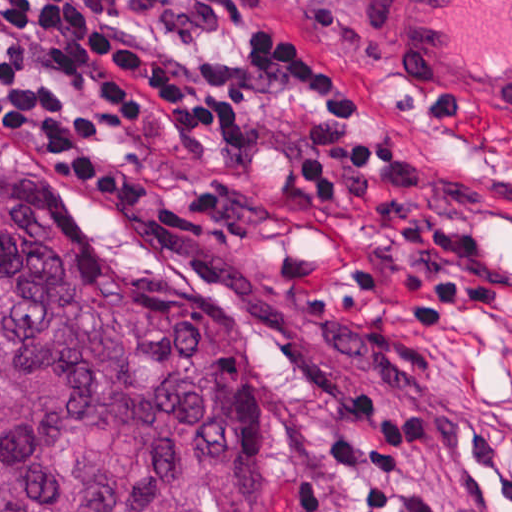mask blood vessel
<instances>
[{
    "mask_svg": "<svg viewBox=\"0 0 512 512\" xmlns=\"http://www.w3.org/2000/svg\"><path fill=\"white\" fill-rule=\"evenodd\" d=\"M389 71L434 123L512 145V0H361Z\"/></svg>",
    "mask_w": 512,
    "mask_h": 512,
    "instance_id": "blood-vessel-1",
    "label": "blood vessel"
}]
</instances>
